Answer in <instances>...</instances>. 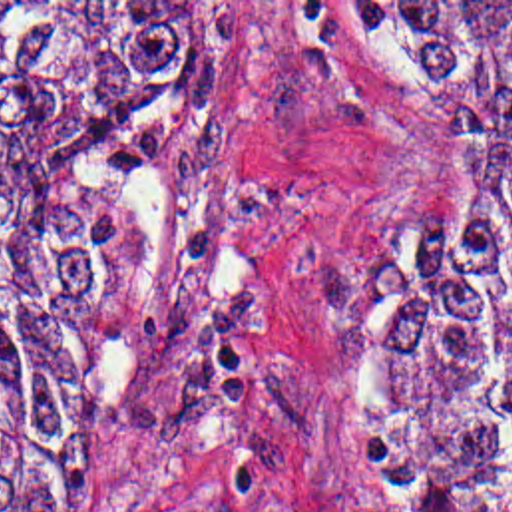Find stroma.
<instances>
[{"mask_svg": "<svg viewBox=\"0 0 512 512\" xmlns=\"http://www.w3.org/2000/svg\"><path fill=\"white\" fill-rule=\"evenodd\" d=\"M232 2V62L132 181L128 273L68 398L82 512H399L337 428L325 362L425 227L417 121L323 2Z\"/></svg>", "mask_w": 512, "mask_h": 512, "instance_id": "1", "label": "stroma"}]
</instances>
